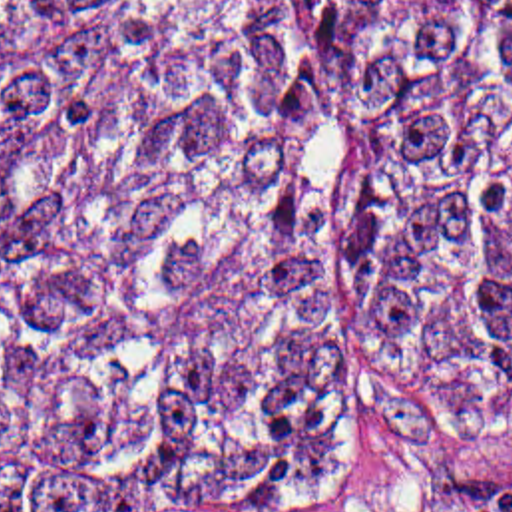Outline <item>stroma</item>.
<instances>
[{
  "instance_id": "obj_1",
  "label": "stroma",
  "mask_w": 512,
  "mask_h": 512,
  "mask_svg": "<svg viewBox=\"0 0 512 512\" xmlns=\"http://www.w3.org/2000/svg\"><path fill=\"white\" fill-rule=\"evenodd\" d=\"M461 481H512V396H411L381 412L325 512H435Z\"/></svg>"
}]
</instances>
